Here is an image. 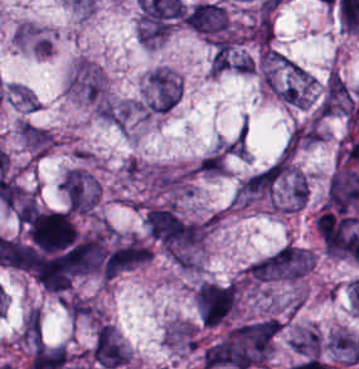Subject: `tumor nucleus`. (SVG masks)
<instances>
[{
    "label": "tumor nucleus",
    "instance_id": "tumor-nucleus-7",
    "mask_svg": "<svg viewBox=\"0 0 359 369\" xmlns=\"http://www.w3.org/2000/svg\"><path fill=\"white\" fill-rule=\"evenodd\" d=\"M179 96V82L172 71L157 67L147 80L144 111L161 114L170 111Z\"/></svg>",
    "mask_w": 359,
    "mask_h": 369
},
{
    "label": "tumor nucleus",
    "instance_id": "tumor-nucleus-13",
    "mask_svg": "<svg viewBox=\"0 0 359 369\" xmlns=\"http://www.w3.org/2000/svg\"><path fill=\"white\" fill-rule=\"evenodd\" d=\"M294 352L308 359H319L320 335L313 327L299 330L293 339Z\"/></svg>",
    "mask_w": 359,
    "mask_h": 369
},
{
    "label": "tumor nucleus",
    "instance_id": "tumor-nucleus-6",
    "mask_svg": "<svg viewBox=\"0 0 359 369\" xmlns=\"http://www.w3.org/2000/svg\"><path fill=\"white\" fill-rule=\"evenodd\" d=\"M88 357L99 367H121L127 361L126 349L110 323H96Z\"/></svg>",
    "mask_w": 359,
    "mask_h": 369
},
{
    "label": "tumor nucleus",
    "instance_id": "tumor-nucleus-8",
    "mask_svg": "<svg viewBox=\"0 0 359 369\" xmlns=\"http://www.w3.org/2000/svg\"><path fill=\"white\" fill-rule=\"evenodd\" d=\"M285 174L280 158L250 175L236 190V201L249 202L270 196Z\"/></svg>",
    "mask_w": 359,
    "mask_h": 369
},
{
    "label": "tumor nucleus",
    "instance_id": "tumor-nucleus-1",
    "mask_svg": "<svg viewBox=\"0 0 359 369\" xmlns=\"http://www.w3.org/2000/svg\"><path fill=\"white\" fill-rule=\"evenodd\" d=\"M280 331L279 318L264 317L241 322L222 336L237 369L265 366Z\"/></svg>",
    "mask_w": 359,
    "mask_h": 369
},
{
    "label": "tumor nucleus",
    "instance_id": "tumor-nucleus-4",
    "mask_svg": "<svg viewBox=\"0 0 359 369\" xmlns=\"http://www.w3.org/2000/svg\"><path fill=\"white\" fill-rule=\"evenodd\" d=\"M64 208L71 213H91L98 201V185L94 177L71 168L59 184Z\"/></svg>",
    "mask_w": 359,
    "mask_h": 369
},
{
    "label": "tumor nucleus",
    "instance_id": "tumor-nucleus-14",
    "mask_svg": "<svg viewBox=\"0 0 359 369\" xmlns=\"http://www.w3.org/2000/svg\"><path fill=\"white\" fill-rule=\"evenodd\" d=\"M19 337L30 347L43 341L40 317L36 308H29L20 326Z\"/></svg>",
    "mask_w": 359,
    "mask_h": 369
},
{
    "label": "tumor nucleus",
    "instance_id": "tumor-nucleus-12",
    "mask_svg": "<svg viewBox=\"0 0 359 369\" xmlns=\"http://www.w3.org/2000/svg\"><path fill=\"white\" fill-rule=\"evenodd\" d=\"M164 342L171 346L196 347L197 329L194 323L174 321L164 329Z\"/></svg>",
    "mask_w": 359,
    "mask_h": 369
},
{
    "label": "tumor nucleus",
    "instance_id": "tumor-nucleus-9",
    "mask_svg": "<svg viewBox=\"0 0 359 369\" xmlns=\"http://www.w3.org/2000/svg\"><path fill=\"white\" fill-rule=\"evenodd\" d=\"M68 88L90 102L103 103L105 79L92 63L79 62L68 81Z\"/></svg>",
    "mask_w": 359,
    "mask_h": 369
},
{
    "label": "tumor nucleus",
    "instance_id": "tumor-nucleus-2",
    "mask_svg": "<svg viewBox=\"0 0 359 369\" xmlns=\"http://www.w3.org/2000/svg\"><path fill=\"white\" fill-rule=\"evenodd\" d=\"M308 250L285 244L254 262L249 277L254 282H280L302 278L312 267Z\"/></svg>",
    "mask_w": 359,
    "mask_h": 369
},
{
    "label": "tumor nucleus",
    "instance_id": "tumor-nucleus-11",
    "mask_svg": "<svg viewBox=\"0 0 359 369\" xmlns=\"http://www.w3.org/2000/svg\"><path fill=\"white\" fill-rule=\"evenodd\" d=\"M327 346L347 364L359 362V343L346 330H338L327 337Z\"/></svg>",
    "mask_w": 359,
    "mask_h": 369
},
{
    "label": "tumor nucleus",
    "instance_id": "tumor-nucleus-10",
    "mask_svg": "<svg viewBox=\"0 0 359 369\" xmlns=\"http://www.w3.org/2000/svg\"><path fill=\"white\" fill-rule=\"evenodd\" d=\"M353 109V96L350 88L340 75L331 71L326 79L318 105L319 114L343 115Z\"/></svg>",
    "mask_w": 359,
    "mask_h": 369
},
{
    "label": "tumor nucleus",
    "instance_id": "tumor-nucleus-5",
    "mask_svg": "<svg viewBox=\"0 0 359 369\" xmlns=\"http://www.w3.org/2000/svg\"><path fill=\"white\" fill-rule=\"evenodd\" d=\"M10 44L15 51L37 57H50L54 52L53 32L41 23L22 19L10 32Z\"/></svg>",
    "mask_w": 359,
    "mask_h": 369
},
{
    "label": "tumor nucleus",
    "instance_id": "tumor-nucleus-3",
    "mask_svg": "<svg viewBox=\"0 0 359 369\" xmlns=\"http://www.w3.org/2000/svg\"><path fill=\"white\" fill-rule=\"evenodd\" d=\"M184 25L208 40L231 38V19L219 3L200 1L184 9Z\"/></svg>",
    "mask_w": 359,
    "mask_h": 369
},
{
    "label": "tumor nucleus",
    "instance_id": "tumor-nucleus-15",
    "mask_svg": "<svg viewBox=\"0 0 359 369\" xmlns=\"http://www.w3.org/2000/svg\"><path fill=\"white\" fill-rule=\"evenodd\" d=\"M198 170L205 174L219 175L226 172V163L221 149H213L198 163Z\"/></svg>",
    "mask_w": 359,
    "mask_h": 369
},
{
    "label": "tumor nucleus",
    "instance_id": "tumor-nucleus-16",
    "mask_svg": "<svg viewBox=\"0 0 359 369\" xmlns=\"http://www.w3.org/2000/svg\"><path fill=\"white\" fill-rule=\"evenodd\" d=\"M217 149L227 155L243 157L247 152L246 141L243 133L241 132L217 144Z\"/></svg>",
    "mask_w": 359,
    "mask_h": 369
}]
</instances>
